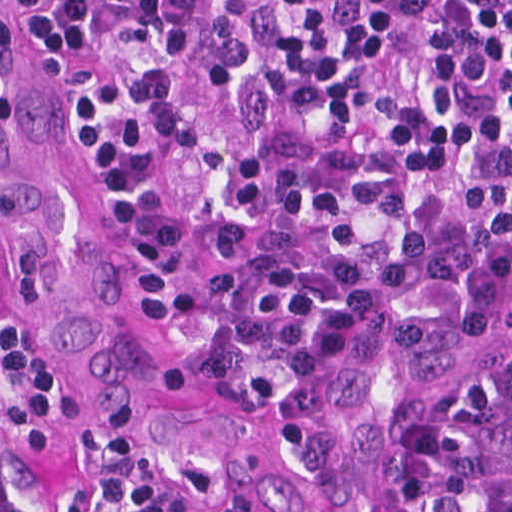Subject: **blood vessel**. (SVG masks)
Returning a JSON list of instances; mask_svg holds the SVG:
<instances>
[{"label": "blood vessel", "instance_id": "1", "mask_svg": "<svg viewBox=\"0 0 512 512\" xmlns=\"http://www.w3.org/2000/svg\"><path fill=\"white\" fill-rule=\"evenodd\" d=\"M0 218L38 320L101 419L230 508L276 498L286 437L259 381L167 338L122 258L40 0H0Z\"/></svg>", "mask_w": 512, "mask_h": 512}]
</instances>
